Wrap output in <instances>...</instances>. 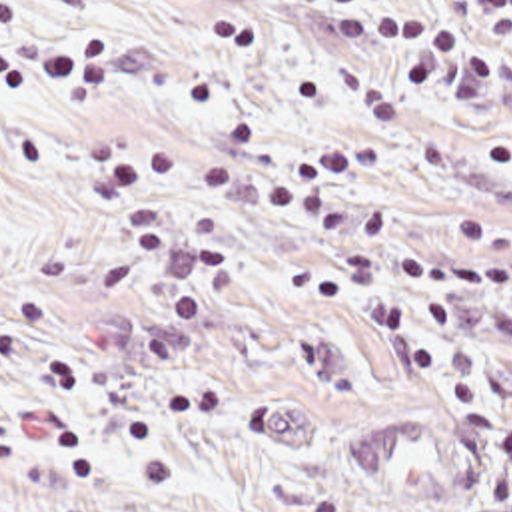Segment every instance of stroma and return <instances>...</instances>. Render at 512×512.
I'll return each instance as SVG.
<instances>
[{
	"mask_svg": "<svg viewBox=\"0 0 512 512\" xmlns=\"http://www.w3.org/2000/svg\"><path fill=\"white\" fill-rule=\"evenodd\" d=\"M22 8L38 32L106 36L116 92L98 108L0 96V512H284L296 491L345 512H512L485 501L491 423L451 411L389 334L314 292L355 240L156 190L178 226L196 206L230 232L236 284L192 353L144 355L200 252L170 250L130 292L108 290L100 266L128 222L86 160V140L104 134L226 166L375 142L383 170L339 192L383 206L395 242L451 252L455 214H512V42L481 96L425 98L407 80L409 54L349 50L334 32L361 18L453 28L469 20L455 0ZM397 282L441 365L489 387L512 421V284L461 294L463 328L439 340Z\"/></svg>",
	"mask_w": 512,
	"mask_h": 512,
	"instance_id": "1",
	"label": "stroma"
}]
</instances>
